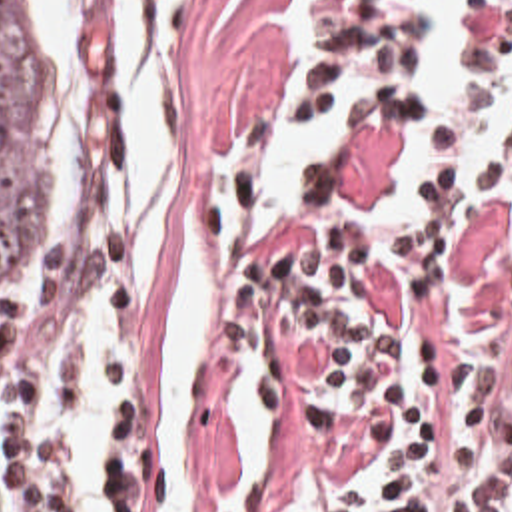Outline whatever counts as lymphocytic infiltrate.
Returning a JSON list of instances; mask_svg holds the SVG:
<instances>
[{
	"mask_svg": "<svg viewBox=\"0 0 512 512\" xmlns=\"http://www.w3.org/2000/svg\"><path fill=\"white\" fill-rule=\"evenodd\" d=\"M428 5L430 0L328 1L300 121L310 119L314 99L360 59L416 69ZM464 61L484 71L512 65V0H470ZM422 109L420 97L380 87L352 129L402 125ZM394 185L322 219L308 237L292 279V354L302 390L356 422L392 486H428L452 458L488 444L486 396L436 352L374 328L362 295V261L386 257L418 275L442 271L484 195L512 187V145L476 195L466 189V175L454 171L432 183L414 221L366 231L364 217ZM0 452L7 486L25 512H70L72 436L51 416L45 338L11 384L0 388ZM106 512H120L110 317ZM402 512H512V448L464 482L418 494Z\"/></svg>",
	"mask_w": 512,
	"mask_h": 512,
	"instance_id": "f902f5d3",
	"label": "lymphocytic infiltrate"
}]
</instances>
